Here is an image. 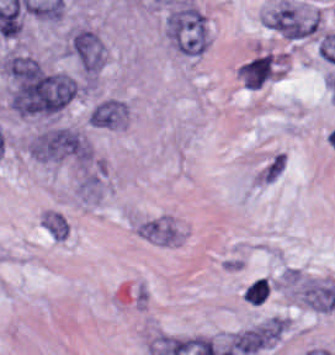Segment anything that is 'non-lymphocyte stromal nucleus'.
Segmentation results:
<instances>
[{
	"label": "non-lymphocyte stromal nucleus",
	"mask_w": 335,
	"mask_h": 355,
	"mask_svg": "<svg viewBox=\"0 0 335 355\" xmlns=\"http://www.w3.org/2000/svg\"><path fill=\"white\" fill-rule=\"evenodd\" d=\"M127 113L124 100L108 97L93 104L87 119L99 127H115L124 121Z\"/></svg>",
	"instance_id": "obj_6"
},
{
	"label": "non-lymphocyte stromal nucleus",
	"mask_w": 335,
	"mask_h": 355,
	"mask_svg": "<svg viewBox=\"0 0 335 355\" xmlns=\"http://www.w3.org/2000/svg\"><path fill=\"white\" fill-rule=\"evenodd\" d=\"M236 351L252 355L271 343V329L269 325L239 331L232 337Z\"/></svg>",
	"instance_id": "obj_7"
},
{
	"label": "non-lymphocyte stromal nucleus",
	"mask_w": 335,
	"mask_h": 355,
	"mask_svg": "<svg viewBox=\"0 0 335 355\" xmlns=\"http://www.w3.org/2000/svg\"><path fill=\"white\" fill-rule=\"evenodd\" d=\"M134 234L156 246H178L182 243V226L171 213L143 215L133 221Z\"/></svg>",
	"instance_id": "obj_3"
},
{
	"label": "non-lymphocyte stromal nucleus",
	"mask_w": 335,
	"mask_h": 355,
	"mask_svg": "<svg viewBox=\"0 0 335 355\" xmlns=\"http://www.w3.org/2000/svg\"><path fill=\"white\" fill-rule=\"evenodd\" d=\"M239 73L249 89H258L272 73V56L268 54L241 65Z\"/></svg>",
	"instance_id": "obj_8"
},
{
	"label": "non-lymphocyte stromal nucleus",
	"mask_w": 335,
	"mask_h": 355,
	"mask_svg": "<svg viewBox=\"0 0 335 355\" xmlns=\"http://www.w3.org/2000/svg\"><path fill=\"white\" fill-rule=\"evenodd\" d=\"M269 286L263 278L253 280L243 294L247 303L261 304L267 297Z\"/></svg>",
	"instance_id": "obj_11"
},
{
	"label": "non-lymphocyte stromal nucleus",
	"mask_w": 335,
	"mask_h": 355,
	"mask_svg": "<svg viewBox=\"0 0 335 355\" xmlns=\"http://www.w3.org/2000/svg\"><path fill=\"white\" fill-rule=\"evenodd\" d=\"M43 224L51 236L57 240H65L67 237L68 223L62 214L49 212L43 218Z\"/></svg>",
	"instance_id": "obj_10"
},
{
	"label": "non-lymphocyte stromal nucleus",
	"mask_w": 335,
	"mask_h": 355,
	"mask_svg": "<svg viewBox=\"0 0 335 355\" xmlns=\"http://www.w3.org/2000/svg\"><path fill=\"white\" fill-rule=\"evenodd\" d=\"M298 296L312 310L331 311L335 308V285L318 278L298 282Z\"/></svg>",
	"instance_id": "obj_5"
},
{
	"label": "non-lymphocyte stromal nucleus",
	"mask_w": 335,
	"mask_h": 355,
	"mask_svg": "<svg viewBox=\"0 0 335 355\" xmlns=\"http://www.w3.org/2000/svg\"><path fill=\"white\" fill-rule=\"evenodd\" d=\"M70 48L87 73H95L102 66L103 48L92 30L80 29L75 33Z\"/></svg>",
	"instance_id": "obj_4"
},
{
	"label": "non-lymphocyte stromal nucleus",
	"mask_w": 335,
	"mask_h": 355,
	"mask_svg": "<svg viewBox=\"0 0 335 355\" xmlns=\"http://www.w3.org/2000/svg\"><path fill=\"white\" fill-rule=\"evenodd\" d=\"M34 157L88 161L92 149L81 132L72 125H53L36 133L28 144Z\"/></svg>",
	"instance_id": "obj_2"
},
{
	"label": "non-lymphocyte stromal nucleus",
	"mask_w": 335,
	"mask_h": 355,
	"mask_svg": "<svg viewBox=\"0 0 335 355\" xmlns=\"http://www.w3.org/2000/svg\"><path fill=\"white\" fill-rule=\"evenodd\" d=\"M285 169V151L276 150L259 167L254 175L255 184L272 185Z\"/></svg>",
	"instance_id": "obj_9"
},
{
	"label": "non-lymphocyte stromal nucleus",
	"mask_w": 335,
	"mask_h": 355,
	"mask_svg": "<svg viewBox=\"0 0 335 355\" xmlns=\"http://www.w3.org/2000/svg\"><path fill=\"white\" fill-rule=\"evenodd\" d=\"M166 32L169 40L185 55L194 57L208 47L207 17L193 2L172 8L166 20Z\"/></svg>",
	"instance_id": "obj_1"
}]
</instances>
